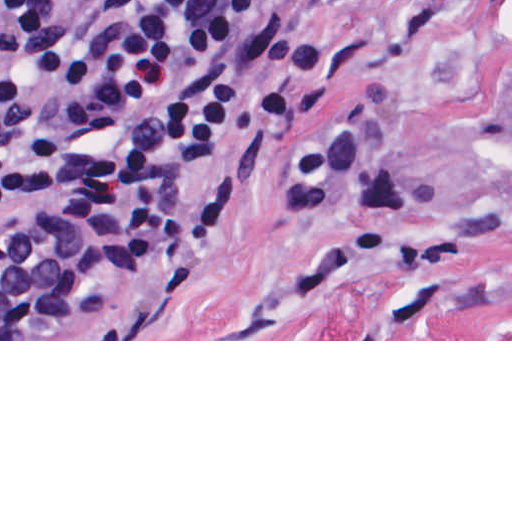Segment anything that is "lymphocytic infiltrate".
<instances>
[{
  "label": "lymphocytic infiltrate",
  "instance_id": "lymphocytic-infiltrate-1",
  "mask_svg": "<svg viewBox=\"0 0 512 512\" xmlns=\"http://www.w3.org/2000/svg\"><path fill=\"white\" fill-rule=\"evenodd\" d=\"M244 0H0V237L72 261L124 237L162 261L214 250L227 199L178 221L189 172L225 149L239 107L228 61ZM296 24L288 73L263 89L269 140L327 83Z\"/></svg>",
  "mask_w": 512,
  "mask_h": 512
}]
</instances>
